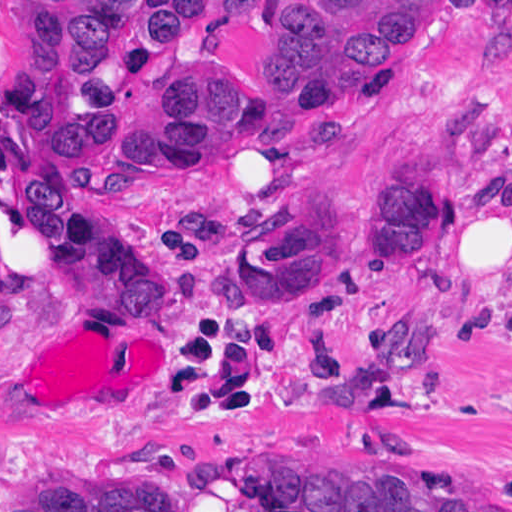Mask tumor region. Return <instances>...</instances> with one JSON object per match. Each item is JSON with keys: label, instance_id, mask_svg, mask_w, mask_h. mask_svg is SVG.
Returning <instances> with one entry per match:
<instances>
[{"label": "tumor region", "instance_id": "tumor-region-1", "mask_svg": "<svg viewBox=\"0 0 512 512\" xmlns=\"http://www.w3.org/2000/svg\"><path fill=\"white\" fill-rule=\"evenodd\" d=\"M244 0H32L0 39L6 143L42 148L68 127L78 155L104 164L144 149L295 138L358 102L403 0H285L271 16L261 70L199 54L126 74ZM512 173L511 161L505 162ZM20 200L37 238L57 252L76 311L123 304L164 320L173 281L150 270L95 199L75 190L57 154L28 161ZM347 214L408 279L444 225V196L422 142L358 177ZM234 272L255 297L323 291L344 266L328 196L302 186L235 250ZM410 270V271H411ZM437 359L429 311L389 312L350 381L307 385L279 364L274 386L311 406L359 408ZM130 454L208 490L222 475L265 512H512L511 491L461 482L404 441H326L209 459ZM7 512H188L182 491L152 472L70 466L34 475Z\"/></svg>", "mask_w": 512, "mask_h": 512}]
</instances>
